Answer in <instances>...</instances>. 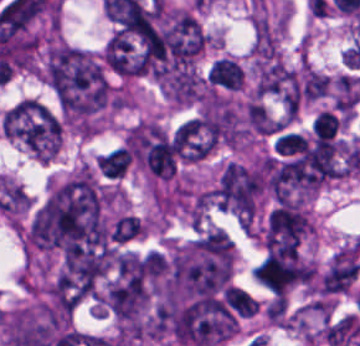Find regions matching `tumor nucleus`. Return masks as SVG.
Instances as JSON below:
<instances>
[{
    "label": "tumor nucleus",
    "mask_w": 360,
    "mask_h": 346,
    "mask_svg": "<svg viewBox=\"0 0 360 346\" xmlns=\"http://www.w3.org/2000/svg\"><path fill=\"white\" fill-rule=\"evenodd\" d=\"M264 179L260 172L229 163L215 188L221 208L245 221H252L258 208Z\"/></svg>",
    "instance_id": "4"
},
{
    "label": "tumor nucleus",
    "mask_w": 360,
    "mask_h": 346,
    "mask_svg": "<svg viewBox=\"0 0 360 346\" xmlns=\"http://www.w3.org/2000/svg\"><path fill=\"white\" fill-rule=\"evenodd\" d=\"M242 79L241 68L229 58L219 57L208 67L207 82L213 87L236 91Z\"/></svg>",
    "instance_id": "7"
},
{
    "label": "tumor nucleus",
    "mask_w": 360,
    "mask_h": 346,
    "mask_svg": "<svg viewBox=\"0 0 360 346\" xmlns=\"http://www.w3.org/2000/svg\"><path fill=\"white\" fill-rule=\"evenodd\" d=\"M255 280L273 293H282L305 276L303 263L292 252L271 254L259 261L253 269Z\"/></svg>",
    "instance_id": "5"
},
{
    "label": "tumor nucleus",
    "mask_w": 360,
    "mask_h": 346,
    "mask_svg": "<svg viewBox=\"0 0 360 346\" xmlns=\"http://www.w3.org/2000/svg\"><path fill=\"white\" fill-rule=\"evenodd\" d=\"M44 78L65 118H87L105 111L114 101L100 56L67 45L50 47Z\"/></svg>",
    "instance_id": "1"
},
{
    "label": "tumor nucleus",
    "mask_w": 360,
    "mask_h": 346,
    "mask_svg": "<svg viewBox=\"0 0 360 346\" xmlns=\"http://www.w3.org/2000/svg\"><path fill=\"white\" fill-rule=\"evenodd\" d=\"M224 295L230 306L239 316H252L258 307L259 301L250 293L239 287L227 286Z\"/></svg>",
    "instance_id": "10"
},
{
    "label": "tumor nucleus",
    "mask_w": 360,
    "mask_h": 346,
    "mask_svg": "<svg viewBox=\"0 0 360 346\" xmlns=\"http://www.w3.org/2000/svg\"><path fill=\"white\" fill-rule=\"evenodd\" d=\"M228 242L205 236L181 246L175 253L162 297L180 301L206 297L224 287L233 269Z\"/></svg>",
    "instance_id": "2"
},
{
    "label": "tumor nucleus",
    "mask_w": 360,
    "mask_h": 346,
    "mask_svg": "<svg viewBox=\"0 0 360 346\" xmlns=\"http://www.w3.org/2000/svg\"><path fill=\"white\" fill-rule=\"evenodd\" d=\"M359 77L340 75L336 80L333 102L338 111L350 113L356 104Z\"/></svg>",
    "instance_id": "8"
},
{
    "label": "tumor nucleus",
    "mask_w": 360,
    "mask_h": 346,
    "mask_svg": "<svg viewBox=\"0 0 360 346\" xmlns=\"http://www.w3.org/2000/svg\"><path fill=\"white\" fill-rule=\"evenodd\" d=\"M359 272L358 251L340 250L322 276L321 291L324 293L347 291Z\"/></svg>",
    "instance_id": "6"
},
{
    "label": "tumor nucleus",
    "mask_w": 360,
    "mask_h": 346,
    "mask_svg": "<svg viewBox=\"0 0 360 346\" xmlns=\"http://www.w3.org/2000/svg\"><path fill=\"white\" fill-rule=\"evenodd\" d=\"M129 154L126 149L116 148L98 158L96 164L104 175L121 178L128 166Z\"/></svg>",
    "instance_id": "9"
},
{
    "label": "tumor nucleus",
    "mask_w": 360,
    "mask_h": 346,
    "mask_svg": "<svg viewBox=\"0 0 360 346\" xmlns=\"http://www.w3.org/2000/svg\"><path fill=\"white\" fill-rule=\"evenodd\" d=\"M140 235H142V224L139 218L122 215L116 221L110 233V239L123 243Z\"/></svg>",
    "instance_id": "11"
},
{
    "label": "tumor nucleus",
    "mask_w": 360,
    "mask_h": 346,
    "mask_svg": "<svg viewBox=\"0 0 360 346\" xmlns=\"http://www.w3.org/2000/svg\"><path fill=\"white\" fill-rule=\"evenodd\" d=\"M0 124L10 138L40 159L60 149L62 129L57 115L39 101L23 98L8 107Z\"/></svg>",
    "instance_id": "3"
},
{
    "label": "tumor nucleus",
    "mask_w": 360,
    "mask_h": 346,
    "mask_svg": "<svg viewBox=\"0 0 360 346\" xmlns=\"http://www.w3.org/2000/svg\"><path fill=\"white\" fill-rule=\"evenodd\" d=\"M328 76L306 66L304 82V98L315 100L325 96Z\"/></svg>",
    "instance_id": "12"
},
{
    "label": "tumor nucleus",
    "mask_w": 360,
    "mask_h": 346,
    "mask_svg": "<svg viewBox=\"0 0 360 346\" xmlns=\"http://www.w3.org/2000/svg\"><path fill=\"white\" fill-rule=\"evenodd\" d=\"M338 120L333 112L320 111L312 121L311 129L314 135L332 136L335 133Z\"/></svg>",
    "instance_id": "13"
}]
</instances>
